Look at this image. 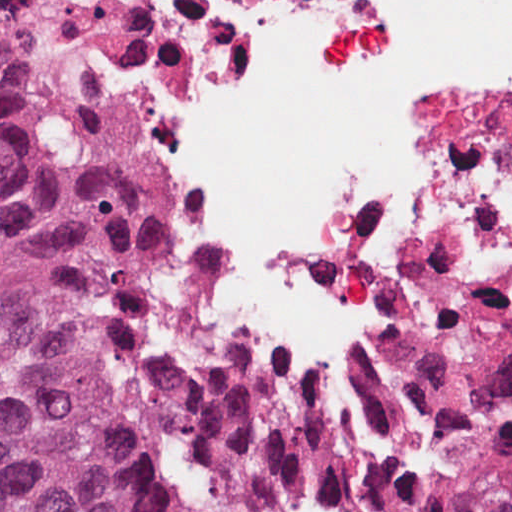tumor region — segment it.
<instances>
[{
	"label": "tumor region",
	"instance_id": "tumor-region-1",
	"mask_svg": "<svg viewBox=\"0 0 512 512\" xmlns=\"http://www.w3.org/2000/svg\"><path fill=\"white\" fill-rule=\"evenodd\" d=\"M18 1L0 0L6 512H420L152 238L136 22Z\"/></svg>",
	"mask_w": 512,
	"mask_h": 512
}]
</instances>
